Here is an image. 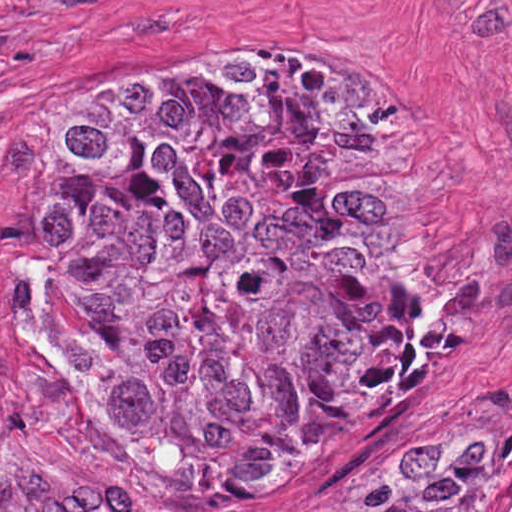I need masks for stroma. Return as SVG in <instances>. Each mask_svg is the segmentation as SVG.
Listing matches in <instances>:
<instances>
[{
    "mask_svg": "<svg viewBox=\"0 0 512 512\" xmlns=\"http://www.w3.org/2000/svg\"><path fill=\"white\" fill-rule=\"evenodd\" d=\"M381 95L439 162L450 265L409 401L353 467L243 494L177 489L57 391V247L39 144L139 68L191 53ZM510 414L512 0H0V512H320L417 414ZM494 512H512L496 507Z\"/></svg>",
    "mask_w": 512,
    "mask_h": 512,
    "instance_id": "35a3bbf8",
    "label": "stroma"
}]
</instances>
